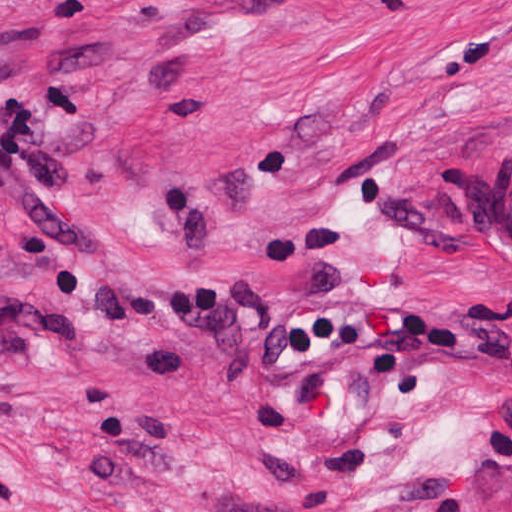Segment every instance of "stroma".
<instances>
[{"label": "stroma", "mask_w": 512, "mask_h": 512, "mask_svg": "<svg viewBox=\"0 0 512 512\" xmlns=\"http://www.w3.org/2000/svg\"><path fill=\"white\" fill-rule=\"evenodd\" d=\"M122 245L0 216V512H512V0H0Z\"/></svg>", "instance_id": "obj_1"}]
</instances>
